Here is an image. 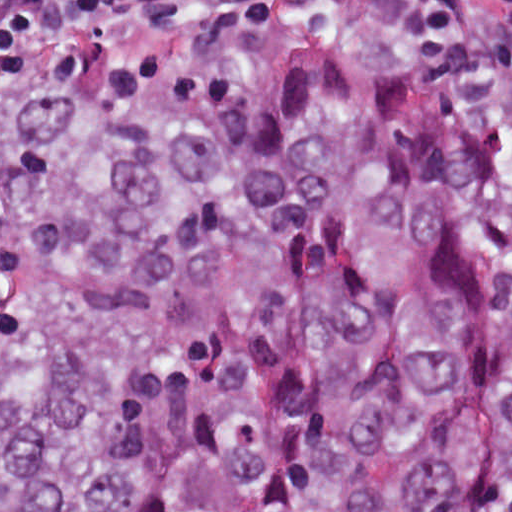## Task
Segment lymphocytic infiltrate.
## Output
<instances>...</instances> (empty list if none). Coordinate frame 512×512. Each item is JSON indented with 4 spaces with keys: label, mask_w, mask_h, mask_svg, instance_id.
Wrapping results in <instances>:
<instances>
[{
    "label": "lymphocytic infiltrate",
    "mask_w": 512,
    "mask_h": 512,
    "mask_svg": "<svg viewBox=\"0 0 512 512\" xmlns=\"http://www.w3.org/2000/svg\"><path fill=\"white\" fill-rule=\"evenodd\" d=\"M151 16H321L512 76V0H0V52Z\"/></svg>",
    "instance_id": "1"
}]
</instances>
